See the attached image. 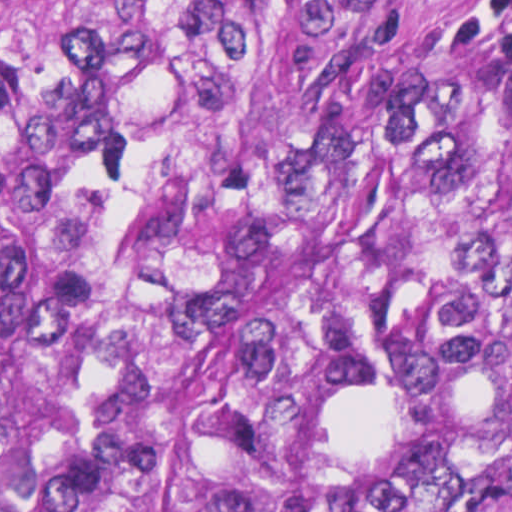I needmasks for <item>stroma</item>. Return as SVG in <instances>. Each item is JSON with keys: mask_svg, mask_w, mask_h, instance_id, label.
I'll return each mask as SVG.
<instances>
[{"mask_svg": "<svg viewBox=\"0 0 512 512\" xmlns=\"http://www.w3.org/2000/svg\"><path fill=\"white\" fill-rule=\"evenodd\" d=\"M461 0H436L441 27L454 33L452 14ZM512 78V68L501 65Z\"/></svg>", "mask_w": 512, "mask_h": 512, "instance_id": "obj_1", "label": "stroma"}]
</instances>
